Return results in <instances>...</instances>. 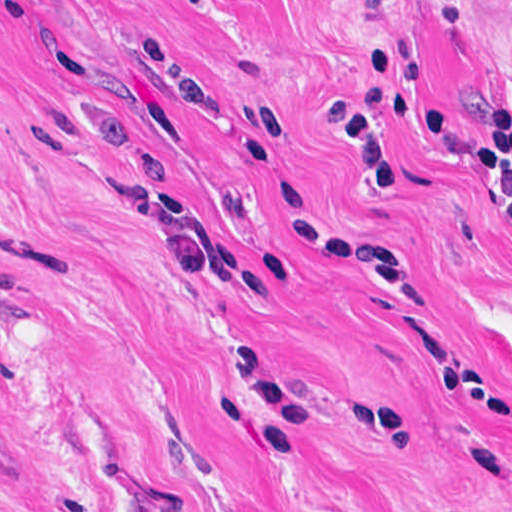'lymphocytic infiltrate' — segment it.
Masks as SVG:
<instances>
[{
    "mask_svg": "<svg viewBox=\"0 0 512 512\" xmlns=\"http://www.w3.org/2000/svg\"><path fill=\"white\" fill-rule=\"evenodd\" d=\"M433 20L440 27H454L462 16L463 0H430Z\"/></svg>",
    "mask_w": 512,
    "mask_h": 512,
    "instance_id": "lymphocytic-infiltrate-1",
    "label": "lymphocytic infiltrate"
}]
</instances>
